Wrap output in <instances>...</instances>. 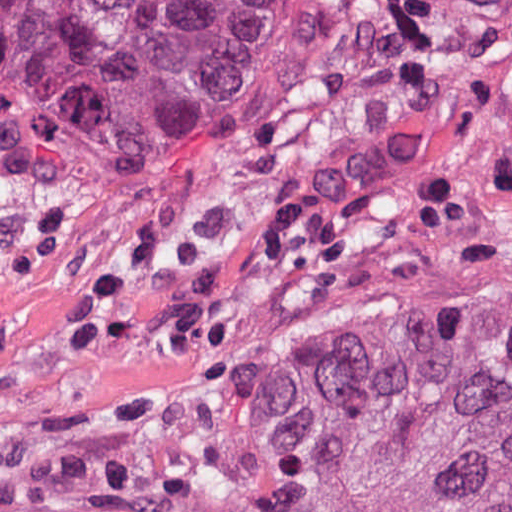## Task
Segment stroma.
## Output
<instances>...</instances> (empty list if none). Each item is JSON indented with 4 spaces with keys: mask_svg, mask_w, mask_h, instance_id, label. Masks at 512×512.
<instances>
[{
    "mask_svg": "<svg viewBox=\"0 0 512 512\" xmlns=\"http://www.w3.org/2000/svg\"><path fill=\"white\" fill-rule=\"evenodd\" d=\"M512 309V49L394 67L280 138L199 136L0 267V446L114 443L295 324Z\"/></svg>",
    "mask_w": 512,
    "mask_h": 512,
    "instance_id": "35a3bbf8",
    "label": "stroma"
}]
</instances>
